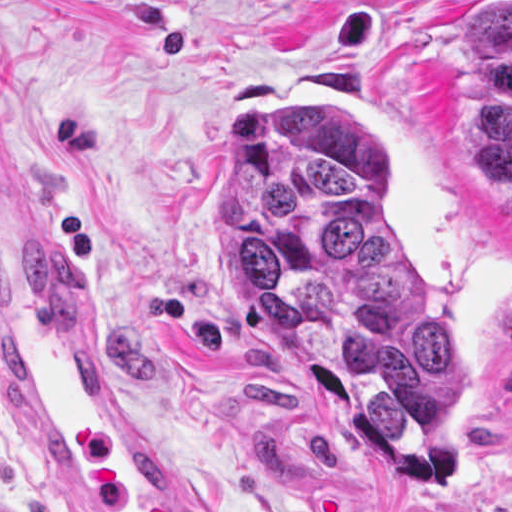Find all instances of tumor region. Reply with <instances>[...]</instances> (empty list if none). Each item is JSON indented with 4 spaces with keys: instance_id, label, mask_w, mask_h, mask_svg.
Returning <instances> with one entry per match:
<instances>
[{
    "instance_id": "1",
    "label": "tumor region",
    "mask_w": 512,
    "mask_h": 512,
    "mask_svg": "<svg viewBox=\"0 0 512 512\" xmlns=\"http://www.w3.org/2000/svg\"><path fill=\"white\" fill-rule=\"evenodd\" d=\"M471 28L457 132L512 201V1ZM226 266L251 332L360 420L398 472L443 469L461 348L378 200V131L355 112H245L214 145Z\"/></svg>"
}]
</instances>
